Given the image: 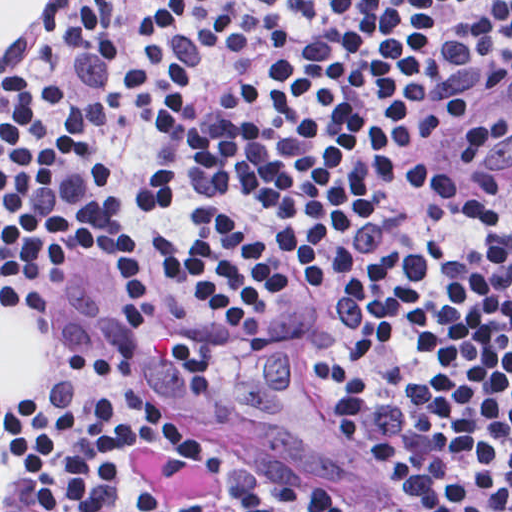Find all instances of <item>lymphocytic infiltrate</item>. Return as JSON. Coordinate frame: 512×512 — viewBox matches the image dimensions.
Segmentation results:
<instances>
[{
  "label": "lymphocytic infiltrate",
  "instance_id": "1",
  "mask_svg": "<svg viewBox=\"0 0 512 512\" xmlns=\"http://www.w3.org/2000/svg\"><path fill=\"white\" fill-rule=\"evenodd\" d=\"M135 184L103 38L65 13L0 76V303L145 284L199 338L252 340L305 294L323 391L388 488L325 465L229 470L235 512H512V184L435 155L512 82V1H112ZM165 412L93 347L0 419L21 512L111 491L195 512L137 463Z\"/></svg>",
  "mask_w": 512,
  "mask_h": 512
}]
</instances>
